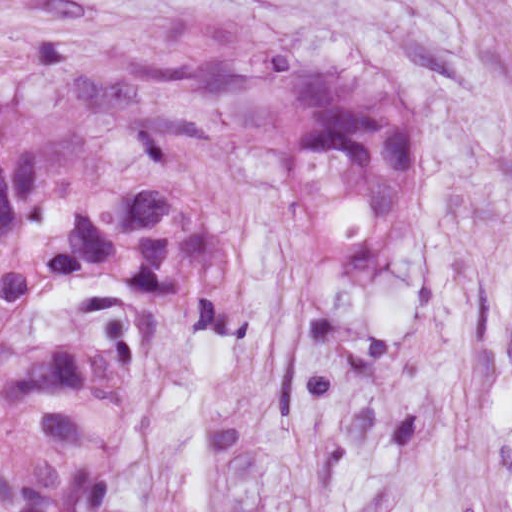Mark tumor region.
Returning a JSON list of instances; mask_svg holds the SVG:
<instances>
[{
  "label": "tumor region",
  "instance_id": "1",
  "mask_svg": "<svg viewBox=\"0 0 512 512\" xmlns=\"http://www.w3.org/2000/svg\"><path fill=\"white\" fill-rule=\"evenodd\" d=\"M281 145L343 278L394 288L414 70L201 7L84 67L0 70V512H107L168 323L256 322V171Z\"/></svg>",
  "mask_w": 512,
  "mask_h": 512
}]
</instances>
